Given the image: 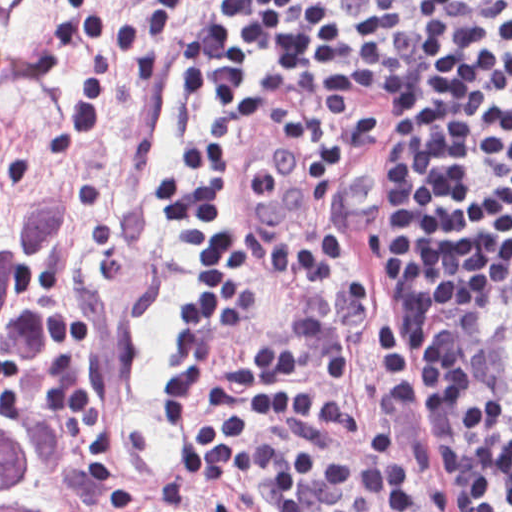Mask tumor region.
<instances>
[{"label": "tumor region", "instance_id": "1", "mask_svg": "<svg viewBox=\"0 0 512 512\" xmlns=\"http://www.w3.org/2000/svg\"><path fill=\"white\" fill-rule=\"evenodd\" d=\"M83 197L70 186L42 208L0 207V362L15 376L40 443L0 418V512H54L56 481L70 497H88L104 484L102 462L76 434L60 398L36 298L44 258L72 232ZM253 510L219 504L200 512Z\"/></svg>", "mask_w": 512, "mask_h": 512}]
</instances>
